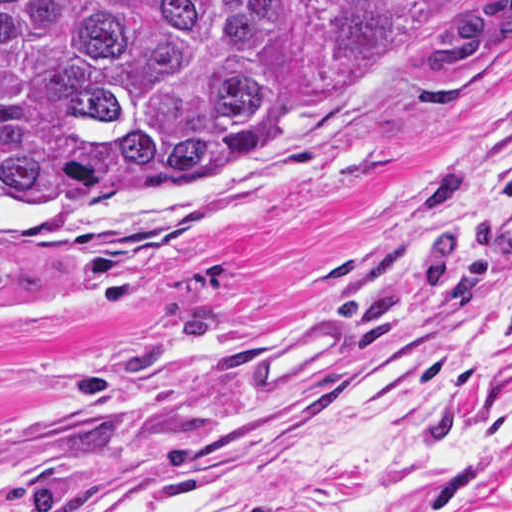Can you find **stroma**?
<instances>
[{"label": "stroma", "instance_id": "stroma-1", "mask_svg": "<svg viewBox=\"0 0 512 512\" xmlns=\"http://www.w3.org/2000/svg\"><path fill=\"white\" fill-rule=\"evenodd\" d=\"M303 106L307 148L248 189L0 231L23 276L0 303V512L231 495L366 369L451 412L474 458L353 512H512V54L387 76L293 0L282 119Z\"/></svg>", "mask_w": 512, "mask_h": 512}]
</instances>
